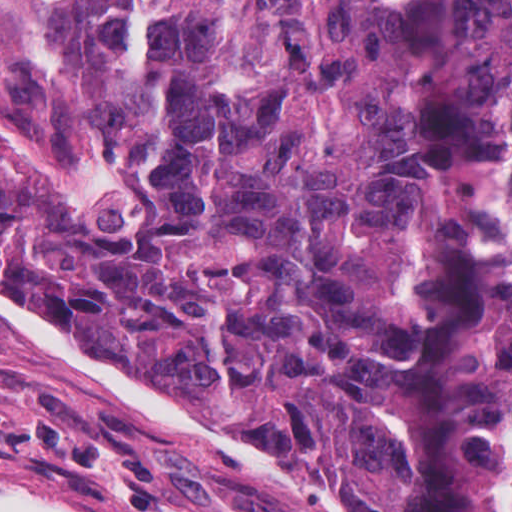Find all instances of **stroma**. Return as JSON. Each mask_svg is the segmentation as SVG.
Segmentation results:
<instances>
[{
    "label": "stroma",
    "instance_id": "obj_1",
    "mask_svg": "<svg viewBox=\"0 0 512 512\" xmlns=\"http://www.w3.org/2000/svg\"><path fill=\"white\" fill-rule=\"evenodd\" d=\"M0 117L48 192L116 204L127 171L76 0H0ZM0 489L78 512H349L224 388L90 351L2 284Z\"/></svg>",
    "mask_w": 512,
    "mask_h": 512
}]
</instances>
